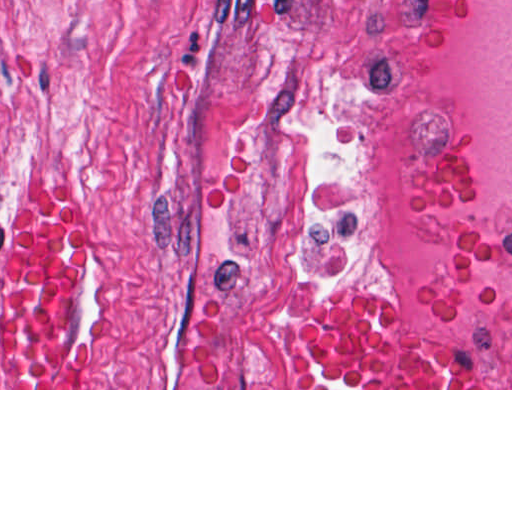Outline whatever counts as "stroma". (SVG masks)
<instances>
[{
  "instance_id": "stroma-1",
  "label": "stroma",
  "mask_w": 512,
  "mask_h": 512,
  "mask_svg": "<svg viewBox=\"0 0 512 512\" xmlns=\"http://www.w3.org/2000/svg\"><path fill=\"white\" fill-rule=\"evenodd\" d=\"M80 204L61 324L80 388H493L405 299L366 153L360 0H0V332L15 228ZM385 298L438 388H317L296 330Z\"/></svg>"
}]
</instances>
